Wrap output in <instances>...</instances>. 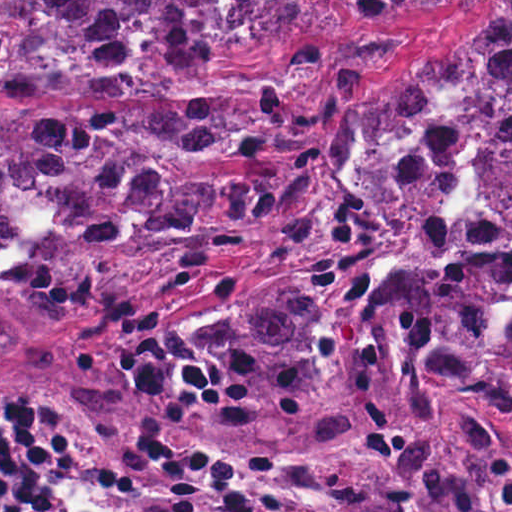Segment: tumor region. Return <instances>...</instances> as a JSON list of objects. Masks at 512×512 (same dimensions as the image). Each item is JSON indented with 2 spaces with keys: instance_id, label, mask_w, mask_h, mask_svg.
Masks as SVG:
<instances>
[{
  "instance_id": "tumor-region-1",
  "label": "tumor region",
  "mask_w": 512,
  "mask_h": 512,
  "mask_svg": "<svg viewBox=\"0 0 512 512\" xmlns=\"http://www.w3.org/2000/svg\"><path fill=\"white\" fill-rule=\"evenodd\" d=\"M329 0H61L0 90H170L304 35ZM372 44L308 74L347 43ZM347 39L295 44L310 99L389 71L342 122L331 172L368 233L165 319L112 358L134 393L218 431L266 496L323 512L512 503V0H350ZM295 93L230 109L0 115V361L42 379L91 303L295 218L320 179Z\"/></svg>"
}]
</instances>
